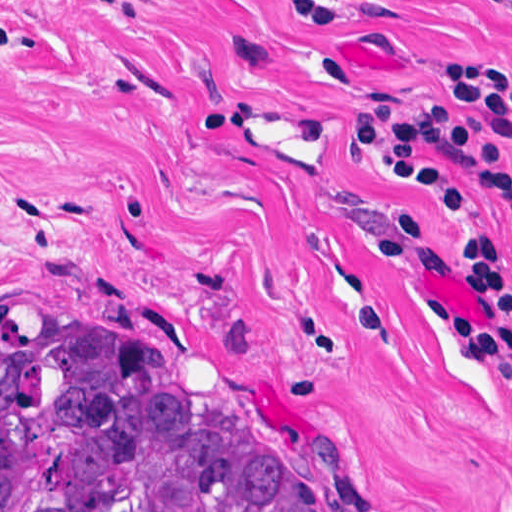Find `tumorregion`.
Segmentation results:
<instances>
[{"label":"tumor region","instance_id":"1","mask_svg":"<svg viewBox=\"0 0 512 512\" xmlns=\"http://www.w3.org/2000/svg\"><path fill=\"white\" fill-rule=\"evenodd\" d=\"M0 512H333L239 409L0 340Z\"/></svg>","mask_w":512,"mask_h":512}]
</instances>
